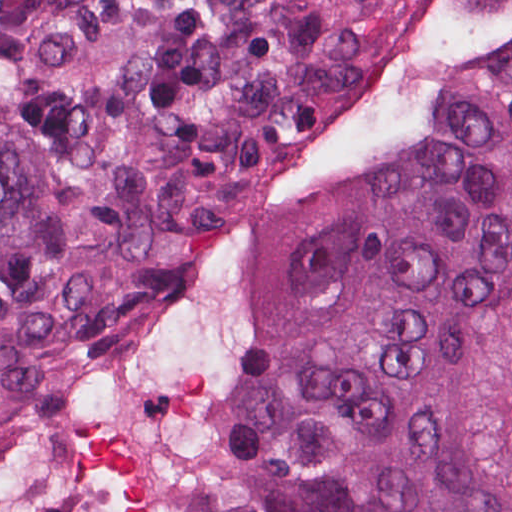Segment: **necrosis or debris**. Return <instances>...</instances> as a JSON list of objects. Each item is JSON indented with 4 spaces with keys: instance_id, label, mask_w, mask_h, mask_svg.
<instances>
[{
    "instance_id": "necrosis-or-debris-1",
    "label": "necrosis or debris",
    "mask_w": 512,
    "mask_h": 512,
    "mask_svg": "<svg viewBox=\"0 0 512 512\" xmlns=\"http://www.w3.org/2000/svg\"><path fill=\"white\" fill-rule=\"evenodd\" d=\"M512 52V0H373L301 121L159 308L0 422V512H211L256 293L379 187L428 114Z\"/></svg>"
}]
</instances>
